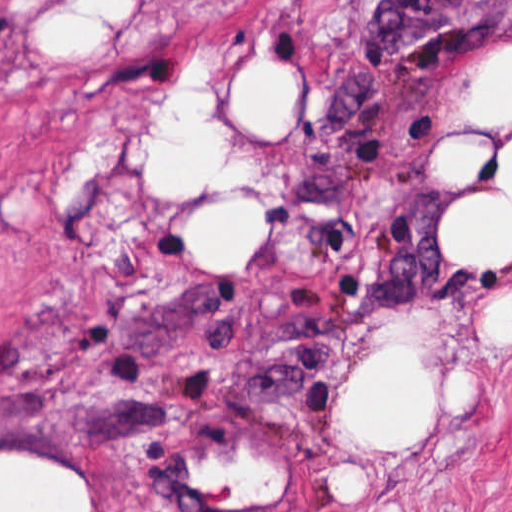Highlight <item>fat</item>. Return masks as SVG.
I'll return each mask as SVG.
<instances>
[{
  "mask_svg": "<svg viewBox=\"0 0 512 512\" xmlns=\"http://www.w3.org/2000/svg\"><path fill=\"white\" fill-rule=\"evenodd\" d=\"M124 15L130 0H86ZM75 8L40 16L36 37L50 49H76L100 32L91 21L72 14ZM230 83L228 100L234 112L255 134H279L298 111L295 79L268 63L258 62ZM471 109L481 119H503L512 110V49L488 57L472 90ZM89 126L85 146L65 165L53 183L55 210H64L72 189L99 175L118 152V136L105 117ZM224 147V133L201 100L180 91L176 108L156 130L154 185L165 200H186L215 166ZM437 159L451 176H466L476 146L444 144ZM512 187V149L508 156ZM233 204L201 214L192 225L191 243L207 265H240L258 249L263 236V212ZM448 249L462 267H501L512 260V208H479L452 216ZM487 326L493 334L512 333V299L491 309ZM458 376L452 399L470 404V380ZM343 416L353 433L373 444L409 446L427 426V398L411 383L406 344L370 358L348 384ZM0 459V512H91L92 490L72 469L32 458ZM214 487L237 485L240 493H275L279 474L248 465L246 458L230 468L216 466L197 472Z\"/></svg>",
  "mask_w": 512,
  "mask_h": 512,
  "instance_id": "1",
  "label": "fat"
}]
</instances>
